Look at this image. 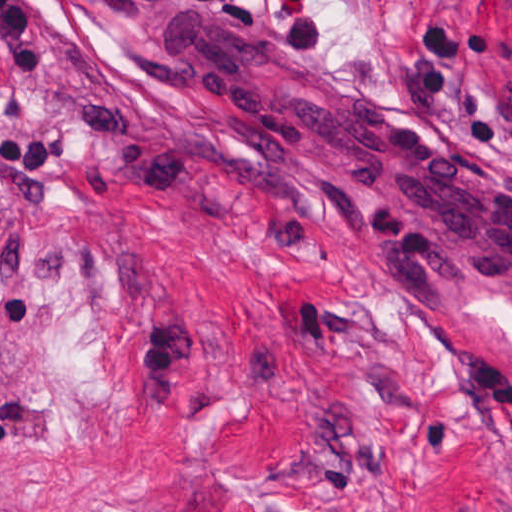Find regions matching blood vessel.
Masks as SVG:
<instances>
[{
    "instance_id": "8fb6f2fc",
    "label": "blood vessel",
    "mask_w": 512,
    "mask_h": 512,
    "mask_svg": "<svg viewBox=\"0 0 512 512\" xmlns=\"http://www.w3.org/2000/svg\"><path fill=\"white\" fill-rule=\"evenodd\" d=\"M140 55L252 143L512 307V175L443 136L288 74L189 12L146 15Z\"/></svg>"
}]
</instances>
